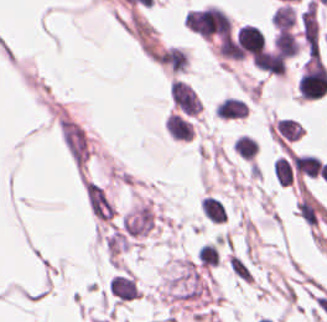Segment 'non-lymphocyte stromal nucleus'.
<instances>
[{"instance_id": "1", "label": "non-lymphocyte stromal nucleus", "mask_w": 327, "mask_h": 322, "mask_svg": "<svg viewBox=\"0 0 327 322\" xmlns=\"http://www.w3.org/2000/svg\"><path fill=\"white\" fill-rule=\"evenodd\" d=\"M84 198L88 209L98 218L108 219L112 210L99 186L90 181H83Z\"/></svg>"}, {"instance_id": "2", "label": "non-lymphocyte stromal nucleus", "mask_w": 327, "mask_h": 322, "mask_svg": "<svg viewBox=\"0 0 327 322\" xmlns=\"http://www.w3.org/2000/svg\"><path fill=\"white\" fill-rule=\"evenodd\" d=\"M227 264L229 269L240 279L246 280L250 282V274L245 266V264L239 260L235 255L232 253L227 259Z\"/></svg>"}]
</instances>
